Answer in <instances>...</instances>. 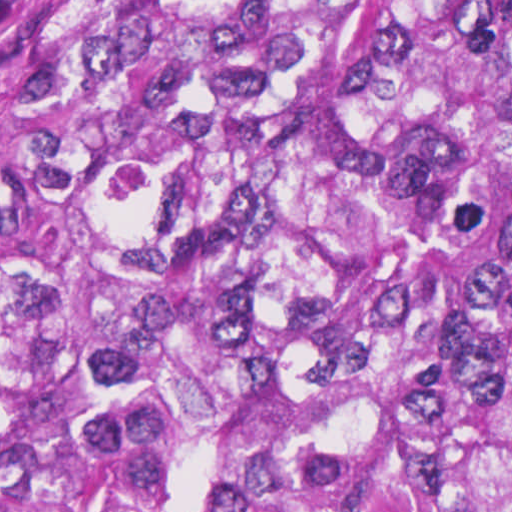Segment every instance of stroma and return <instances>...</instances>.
Returning a JSON list of instances; mask_svg holds the SVG:
<instances>
[{
  "instance_id": "obj_1",
  "label": "stroma",
  "mask_w": 512,
  "mask_h": 512,
  "mask_svg": "<svg viewBox=\"0 0 512 512\" xmlns=\"http://www.w3.org/2000/svg\"><path fill=\"white\" fill-rule=\"evenodd\" d=\"M48 0H0V113L28 97V48Z\"/></svg>"
}]
</instances>
